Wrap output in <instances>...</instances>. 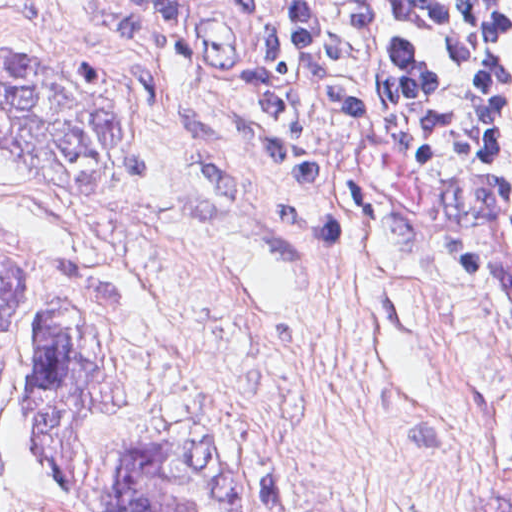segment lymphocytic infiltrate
Segmentation results:
<instances>
[{
    "mask_svg": "<svg viewBox=\"0 0 512 512\" xmlns=\"http://www.w3.org/2000/svg\"><path fill=\"white\" fill-rule=\"evenodd\" d=\"M164 69L195 49L183 4L126 0ZM289 56L382 118L405 121L451 158L512 235V0H248ZM252 129L233 158L270 178L333 188L320 127L251 60Z\"/></svg>",
    "mask_w": 512,
    "mask_h": 512,
    "instance_id": "lymphocytic-infiltrate-1",
    "label": "lymphocytic infiltrate"
}]
</instances>
